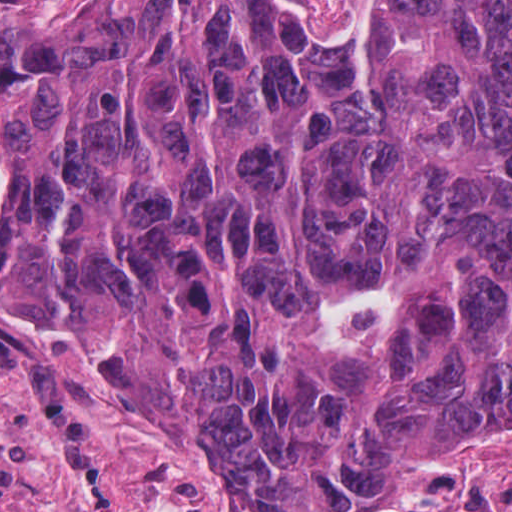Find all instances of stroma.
I'll return each mask as SVG.
<instances>
[{
	"mask_svg": "<svg viewBox=\"0 0 512 512\" xmlns=\"http://www.w3.org/2000/svg\"><path fill=\"white\" fill-rule=\"evenodd\" d=\"M17 163L0 151L2 229ZM512 512V415L318 510L252 484L161 391L0 265V512Z\"/></svg>",
	"mask_w": 512,
	"mask_h": 512,
	"instance_id": "35a3bbf8",
	"label": "stroma"
}]
</instances>
